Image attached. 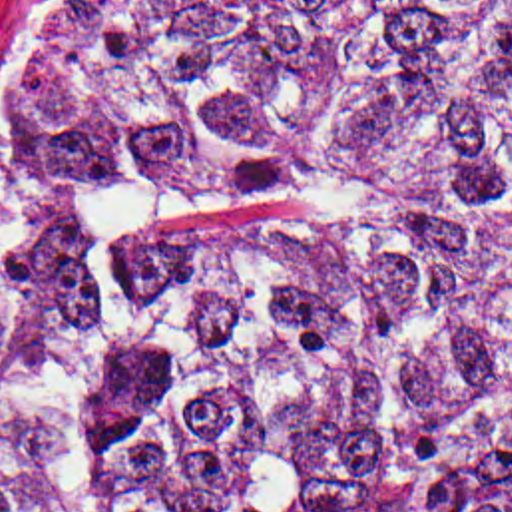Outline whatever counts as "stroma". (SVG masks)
Instances as JSON below:
<instances>
[{"label":"stroma","mask_w":512,"mask_h":512,"mask_svg":"<svg viewBox=\"0 0 512 512\" xmlns=\"http://www.w3.org/2000/svg\"><path fill=\"white\" fill-rule=\"evenodd\" d=\"M127 27L76 31L40 0L0 9V378L26 312V171L50 115Z\"/></svg>","instance_id":"obj_1"}]
</instances>
